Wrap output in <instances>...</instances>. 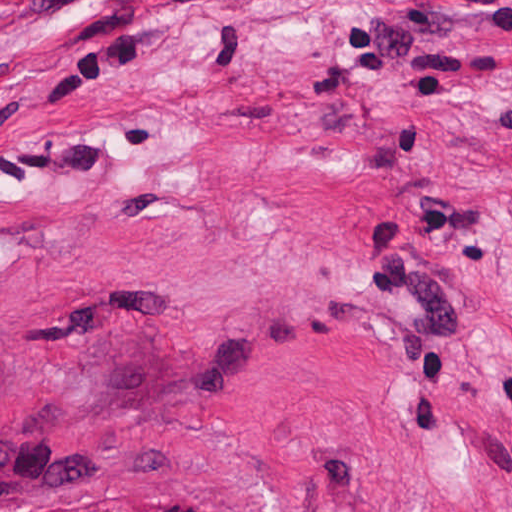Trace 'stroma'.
I'll use <instances>...</instances> for the list:
<instances>
[{
  "label": "stroma",
  "mask_w": 512,
  "mask_h": 512,
  "mask_svg": "<svg viewBox=\"0 0 512 512\" xmlns=\"http://www.w3.org/2000/svg\"><path fill=\"white\" fill-rule=\"evenodd\" d=\"M0 512H512V0H0Z\"/></svg>",
  "instance_id": "35a3bbf8"
}]
</instances>
